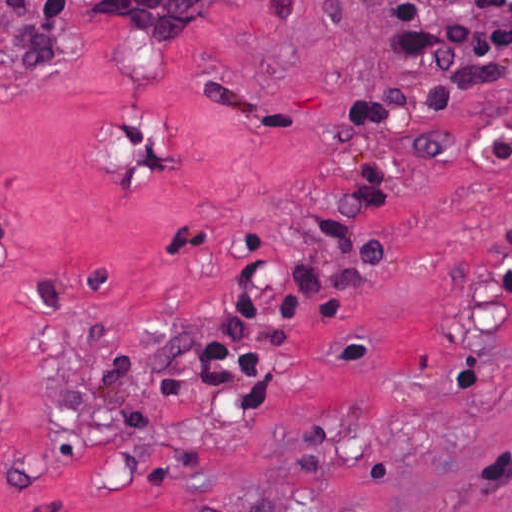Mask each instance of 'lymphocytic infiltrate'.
Returning <instances> with one entry per match:
<instances>
[{
    "instance_id": "1",
    "label": "lymphocytic infiltrate",
    "mask_w": 512,
    "mask_h": 512,
    "mask_svg": "<svg viewBox=\"0 0 512 512\" xmlns=\"http://www.w3.org/2000/svg\"><path fill=\"white\" fill-rule=\"evenodd\" d=\"M14 1L30 11L29 0ZM363 1L389 37V57L384 74L350 94L345 125L351 134L367 136L414 120L447 119L469 95L511 86L512 0ZM95 9L115 18V27L133 37L183 38L215 22L217 0H96ZM33 13L73 21L70 0H44ZM503 127L485 143L483 165ZM451 150L449 135L430 133L402 149L372 154L326 211L304 257L240 263L198 349L201 385L229 395L271 391L292 355L301 308L308 306L320 331L296 361L290 394L358 300L348 304L355 288L380 260L383 236L363 235L362 225L394 198L402 158L442 156ZM4 249L0 228V255ZM0 406L6 419L9 382L1 369Z\"/></svg>"
}]
</instances>
